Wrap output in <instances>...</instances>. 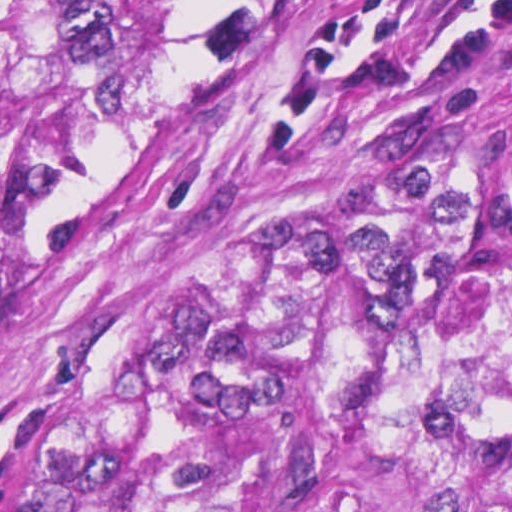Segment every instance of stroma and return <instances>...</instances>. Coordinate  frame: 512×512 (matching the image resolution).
Returning a JSON list of instances; mask_svg holds the SVG:
<instances>
[{
    "instance_id": "stroma-1",
    "label": "stroma",
    "mask_w": 512,
    "mask_h": 512,
    "mask_svg": "<svg viewBox=\"0 0 512 512\" xmlns=\"http://www.w3.org/2000/svg\"><path fill=\"white\" fill-rule=\"evenodd\" d=\"M512 114V0H200L0 319V441L360 278Z\"/></svg>"
}]
</instances>
